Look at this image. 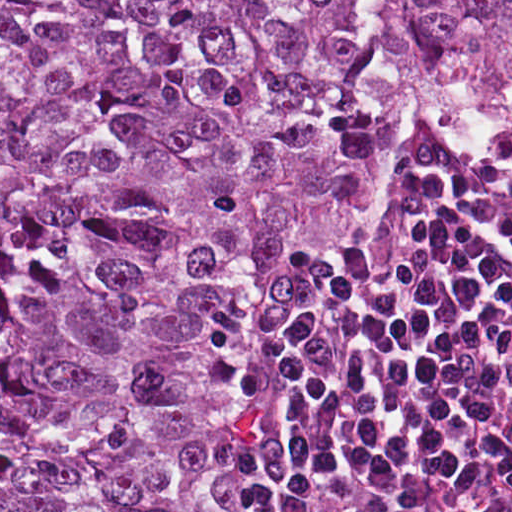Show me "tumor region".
<instances>
[{
    "label": "tumor region",
    "mask_w": 512,
    "mask_h": 512,
    "mask_svg": "<svg viewBox=\"0 0 512 512\" xmlns=\"http://www.w3.org/2000/svg\"><path fill=\"white\" fill-rule=\"evenodd\" d=\"M422 124L512 132V0H0V512H237L261 271Z\"/></svg>",
    "instance_id": "1"
}]
</instances>
